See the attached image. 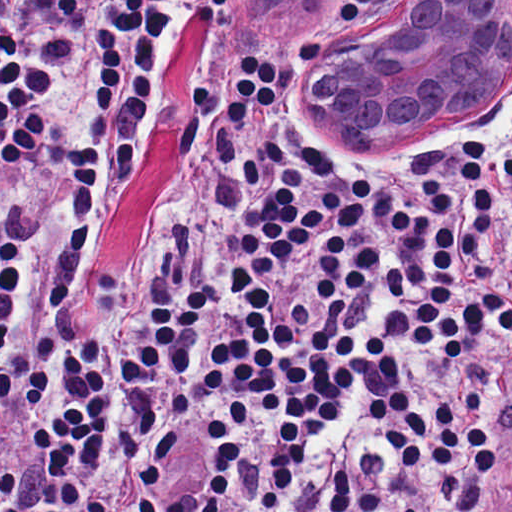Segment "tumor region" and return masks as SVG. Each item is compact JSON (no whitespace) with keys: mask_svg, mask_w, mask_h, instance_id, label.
I'll return each instance as SVG.
<instances>
[{"mask_svg":"<svg viewBox=\"0 0 512 512\" xmlns=\"http://www.w3.org/2000/svg\"><path fill=\"white\" fill-rule=\"evenodd\" d=\"M312 2L313 0H246L245 5L260 15L292 19L304 14Z\"/></svg>","mask_w":512,"mask_h":512,"instance_id":"obj_1","label":"tumor region"}]
</instances>
